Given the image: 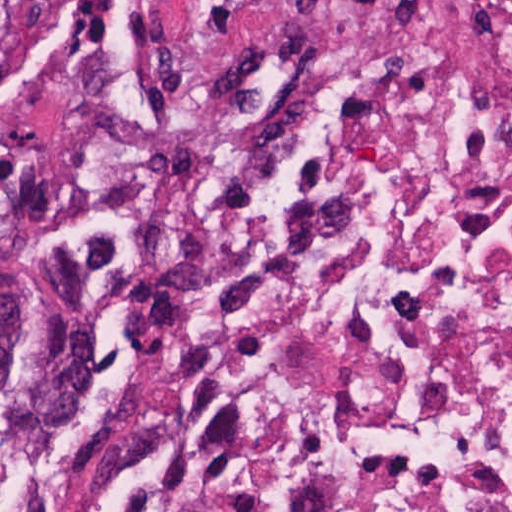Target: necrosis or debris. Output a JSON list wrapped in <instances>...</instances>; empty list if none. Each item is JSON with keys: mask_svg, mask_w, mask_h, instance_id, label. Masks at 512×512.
Masks as SVG:
<instances>
[{"mask_svg": "<svg viewBox=\"0 0 512 512\" xmlns=\"http://www.w3.org/2000/svg\"><path fill=\"white\" fill-rule=\"evenodd\" d=\"M201 129L212 274L0 512H512V0H256Z\"/></svg>", "mask_w": 512, "mask_h": 512, "instance_id": "obj_1", "label": "necrosis or debris"}]
</instances>
